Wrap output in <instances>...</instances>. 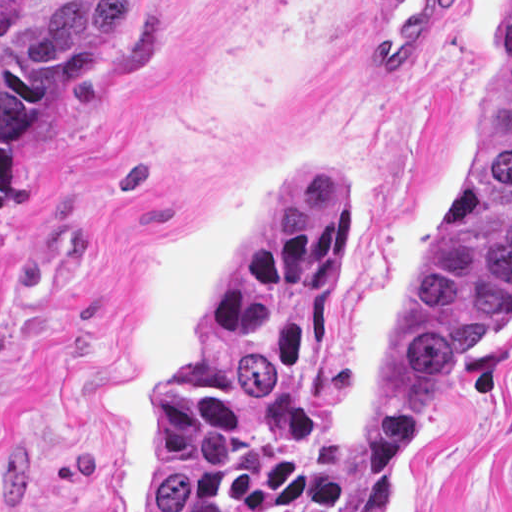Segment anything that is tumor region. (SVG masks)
I'll return each mask as SVG.
<instances>
[{
    "mask_svg": "<svg viewBox=\"0 0 512 512\" xmlns=\"http://www.w3.org/2000/svg\"><path fill=\"white\" fill-rule=\"evenodd\" d=\"M135 0H0V237L21 139ZM346 168L292 167L161 374L150 512H388L512 315V0L469 161L431 215L369 360L366 437L317 428V325L343 255Z\"/></svg>",
    "mask_w": 512,
    "mask_h": 512,
    "instance_id": "obj_1",
    "label": "tumor region"
}]
</instances>
